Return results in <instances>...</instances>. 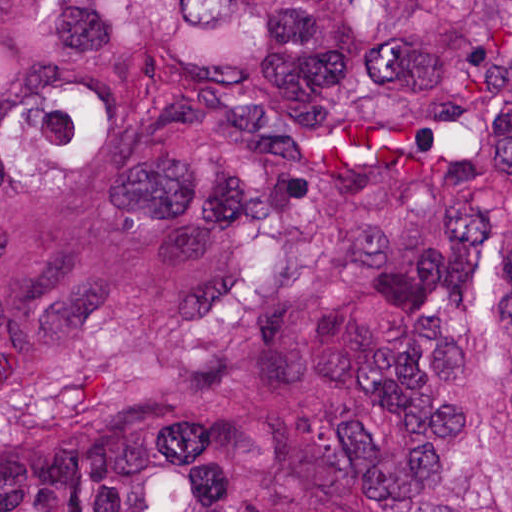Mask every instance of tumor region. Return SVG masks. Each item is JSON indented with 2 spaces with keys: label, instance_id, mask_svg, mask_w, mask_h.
Here are the masks:
<instances>
[{
  "label": "tumor region",
  "instance_id": "1",
  "mask_svg": "<svg viewBox=\"0 0 512 512\" xmlns=\"http://www.w3.org/2000/svg\"><path fill=\"white\" fill-rule=\"evenodd\" d=\"M0 512H512V1H0Z\"/></svg>",
  "mask_w": 512,
  "mask_h": 512
}]
</instances>
